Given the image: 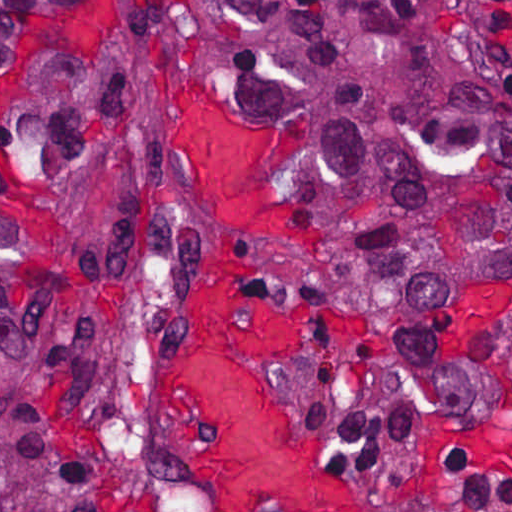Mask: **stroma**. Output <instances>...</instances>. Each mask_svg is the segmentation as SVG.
Here are the masks:
<instances>
[{"instance_id":"1","label":"stroma","mask_w":512,"mask_h":512,"mask_svg":"<svg viewBox=\"0 0 512 512\" xmlns=\"http://www.w3.org/2000/svg\"><path fill=\"white\" fill-rule=\"evenodd\" d=\"M490 5L512 44V0ZM183 94L225 118L274 124L297 141L299 168L288 203L322 236L308 251L259 243L253 254L269 295L311 320L308 353L300 363L261 362L284 400L325 438L332 470L355 496L357 512H428L449 502L454 488L443 462L449 452L466 453L485 473L512 475V291L452 307L447 339L479 387L475 412L424 415L399 447L355 460L344 402L361 389L388 346L383 307L278 287L272 272L316 269L348 255L312 205L310 172L321 159L318 127L245 108L185 76L163 105L151 154L170 160L156 196L178 206L170 225L155 241L133 249L95 308L54 332L37 352L53 359L115 512H213L206 488L164 432L182 320L225 240L198 192L196 165L174 145L181 108L180 102L176 112V101ZM265 512L284 511L271 503Z\"/></svg>"}]
</instances>
